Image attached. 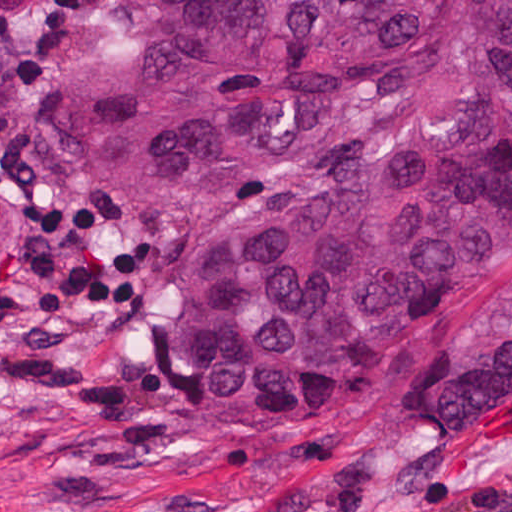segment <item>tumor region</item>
Listing matches in <instances>:
<instances>
[{
  "label": "tumor region",
  "mask_w": 512,
  "mask_h": 512,
  "mask_svg": "<svg viewBox=\"0 0 512 512\" xmlns=\"http://www.w3.org/2000/svg\"><path fill=\"white\" fill-rule=\"evenodd\" d=\"M119 62L79 104L97 166L177 189L286 151L347 78L452 87L355 167L276 192L158 323L216 413L319 406L512 268V0H114Z\"/></svg>",
  "instance_id": "tumor-region-1"
}]
</instances>
